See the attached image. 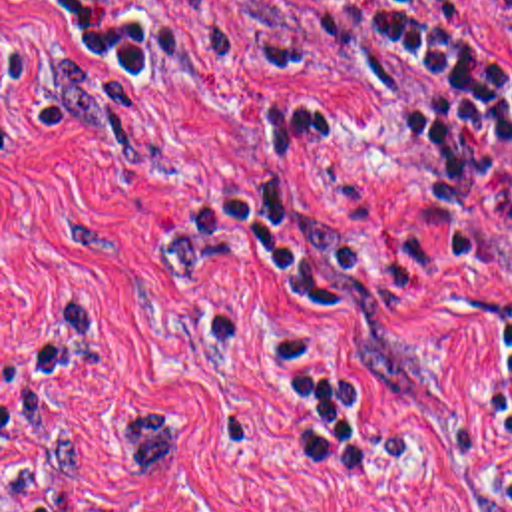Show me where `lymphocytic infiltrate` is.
I'll use <instances>...</instances> for the list:
<instances>
[{
  "mask_svg": "<svg viewBox=\"0 0 512 512\" xmlns=\"http://www.w3.org/2000/svg\"><path fill=\"white\" fill-rule=\"evenodd\" d=\"M512 27V0H504ZM271 35L285 67L362 81L430 121V167L414 202L438 214L458 260L480 244L478 191L512 153V59L480 41L470 0H271ZM267 153L309 159L323 133L301 101H261ZM199 252L281 290L309 316L354 306L366 280L356 236L281 192L241 179L203 192L191 208ZM486 416L512 441V304L482 320Z\"/></svg>",
  "mask_w": 512,
  "mask_h": 512,
  "instance_id": "1",
  "label": "lymphocytic infiltrate"
}]
</instances>
